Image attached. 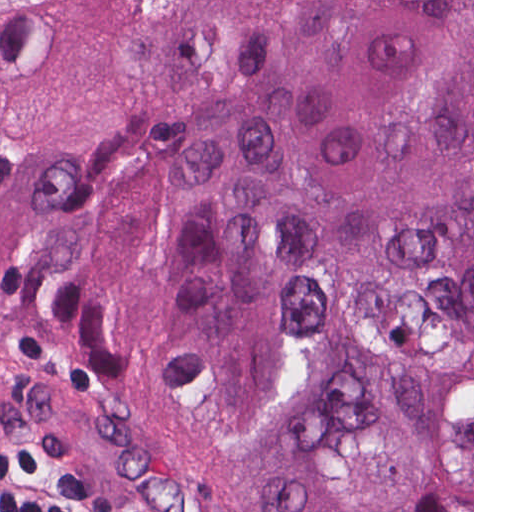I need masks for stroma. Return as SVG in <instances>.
<instances>
[{"instance_id": "obj_1", "label": "stroma", "mask_w": 512, "mask_h": 512, "mask_svg": "<svg viewBox=\"0 0 512 512\" xmlns=\"http://www.w3.org/2000/svg\"><path fill=\"white\" fill-rule=\"evenodd\" d=\"M77 0H0V89ZM0 429L33 437L98 512H252L182 442L44 352L0 342ZM472 512H474V0H472Z\"/></svg>"}]
</instances>
